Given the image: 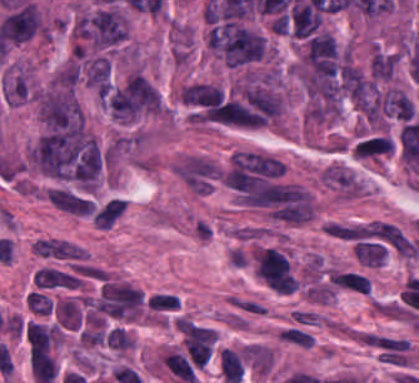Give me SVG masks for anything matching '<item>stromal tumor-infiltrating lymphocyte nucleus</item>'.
Masks as SVG:
<instances>
[{"instance_id": "obj_1", "label": "stromal tumor-infiltrating lymphocyte nucleus", "mask_w": 419, "mask_h": 383, "mask_svg": "<svg viewBox=\"0 0 419 383\" xmlns=\"http://www.w3.org/2000/svg\"><path fill=\"white\" fill-rule=\"evenodd\" d=\"M25 301L30 310L38 315H50L53 311V302L48 292L40 288L28 292Z\"/></svg>"}]
</instances>
